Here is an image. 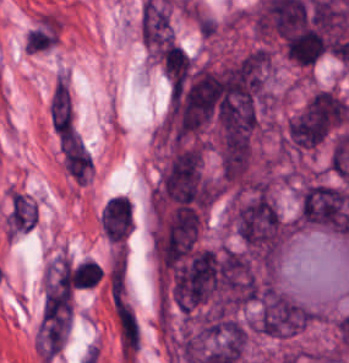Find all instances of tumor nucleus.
Wrapping results in <instances>:
<instances>
[{
	"label": "tumor nucleus",
	"mask_w": 349,
	"mask_h": 363,
	"mask_svg": "<svg viewBox=\"0 0 349 363\" xmlns=\"http://www.w3.org/2000/svg\"><path fill=\"white\" fill-rule=\"evenodd\" d=\"M349 117L346 100L328 87L313 91L291 114L282 134L286 152H305L334 134Z\"/></svg>",
	"instance_id": "2f306a5c"
}]
</instances>
